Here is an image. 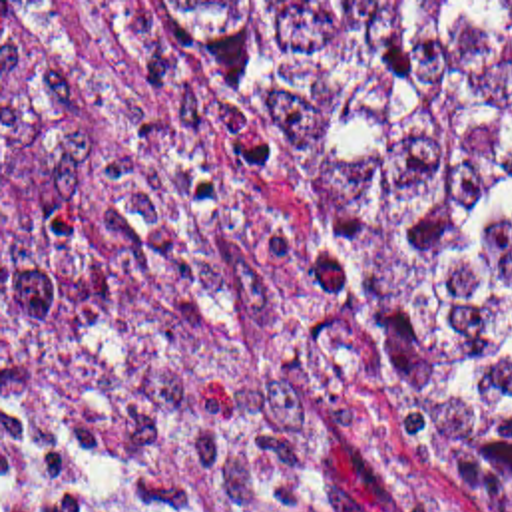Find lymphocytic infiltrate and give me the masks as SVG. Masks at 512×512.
Returning a JSON list of instances; mask_svg holds the SVG:
<instances>
[{
	"mask_svg": "<svg viewBox=\"0 0 512 512\" xmlns=\"http://www.w3.org/2000/svg\"><path fill=\"white\" fill-rule=\"evenodd\" d=\"M2 512H80L56 494L40 492L28 484H2Z\"/></svg>",
	"mask_w": 512,
	"mask_h": 512,
	"instance_id": "lymphocytic-infiltrate-1",
	"label": "lymphocytic infiltrate"
}]
</instances>
